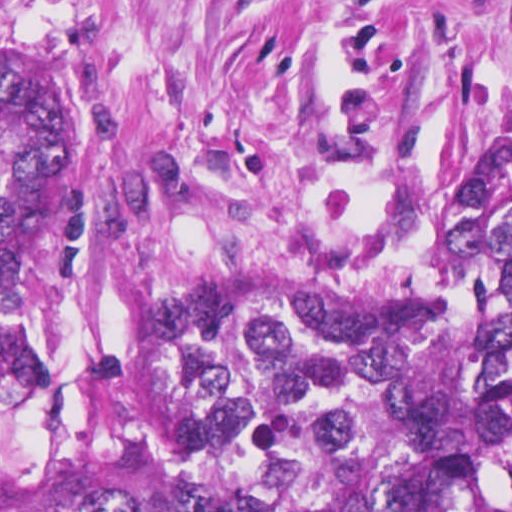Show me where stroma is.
Masks as SVG:
<instances>
[{"mask_svg": "<svg viewBox=\"0 0 512 512\" xmlns=\"http://www.w3.org/2000/svg\"><path fill=\"white\" fill-rule=\"evenodd\" d=\"M0 60L79 111L117 256L383 290L512 195V0H0Z\"/></svg>", "mask_w": 512, "mask_h": 512, "instance_id": "stroma-1", "label": "stroma"}]
</instances>
